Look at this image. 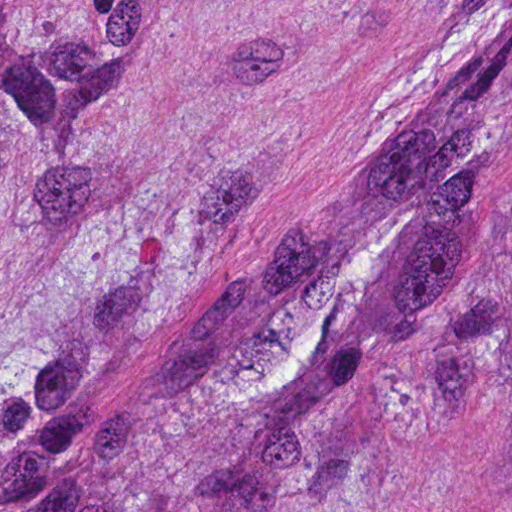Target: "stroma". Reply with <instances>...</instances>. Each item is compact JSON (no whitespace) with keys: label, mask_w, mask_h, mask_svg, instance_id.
Instances as JSON below:
<instances>
[{"label":"stroma","mask_w":512,"mask_h":512,"mask_svg":"<svg viewBox=\"0 0 512 512\" xmlns=\"http://www.w3.org/2000/svg\"><path fill=\"white\" fill-rule=\"evenodd\" d=\"M126 47L83 133L0 197V343L106 235L113 303L202 273L282 160L452 60L512 0H0Z\"/></svg>","instance_id":"35a3bbf8"}]
</instances>
